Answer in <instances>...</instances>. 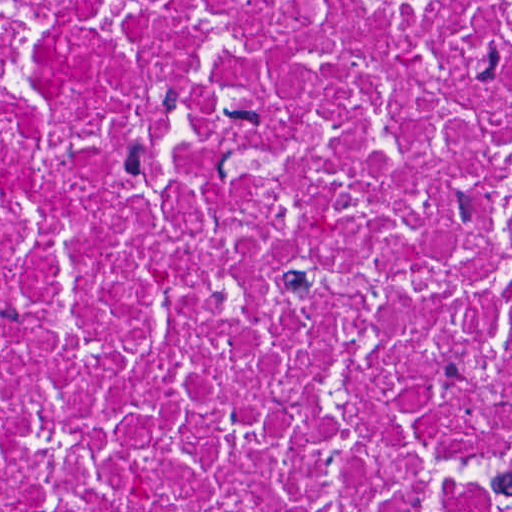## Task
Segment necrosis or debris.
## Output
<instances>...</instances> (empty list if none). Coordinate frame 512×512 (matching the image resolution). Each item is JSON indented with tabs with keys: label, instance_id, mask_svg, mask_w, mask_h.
<instances>
[{
	"label": "necrosis or debris",
	"instance_id": "obj_1",
	"mask_svg": "<svg viewBox=\"0 0 512 512\" xmlns=\"http://www.w3.org/2000/svg\"><path fill=\"white\" fill-rule=\"evenodd\" d=\"M0 512H512V0H0Z\"/></svg>",
	"mask_w": 512,
	"mask_h": 512
}]
</instances>
